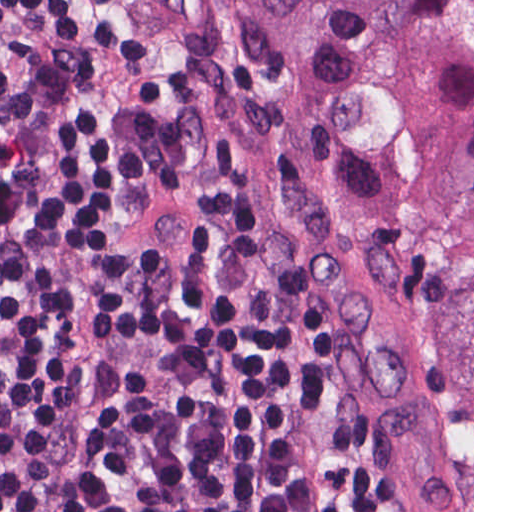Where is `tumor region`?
<instances>
[{"mask_svg":"<svg viewBox=\"0 0 512 512\" xmlns=\"http://www.w3.org/2000/svg\"><path fill=\"white\" fill-rule=\"evenodd\" d=\"M362 166L438 331L437 448L472 512V0H253Z\"/></svg>","mask_w":512,"mask_h":512,"instance_id":"e687c5a6","label":"tumor region"}]
</instances>
